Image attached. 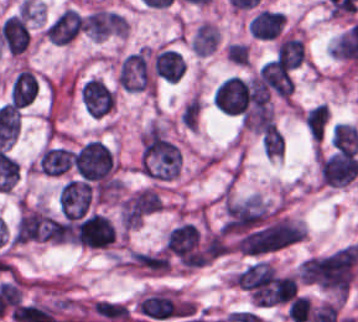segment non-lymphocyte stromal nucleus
Instances as JSON below:
<instances>
[{
	"label": "non-lymphocyte stromal nucleus",
	"instance_id": "non-lymphocyte-stromal-nucleus-1",
	"mask_svg": "<svg viewBox=\"0 0 358 322\" xmlns=\"http://www.w3.org/2000/svg\"><path fill=\"white\" fill-rule=\"evenodd\" d=\"M90 306L106 321L127 322L130 316L124 305L114 300L95 299Z\"/></svg>",
	"mask_w": 358,
	"mask_h": 322
}]
</instances>
